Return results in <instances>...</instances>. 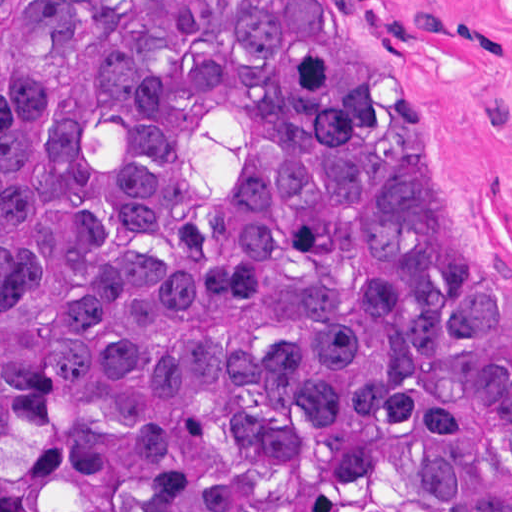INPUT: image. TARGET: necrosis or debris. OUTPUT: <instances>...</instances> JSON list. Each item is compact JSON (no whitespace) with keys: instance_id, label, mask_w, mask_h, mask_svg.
<instances>
[{"instance_id":"1","label":"necrosis or debris","mask_w":512,"mask_h":512,"mask_svg":"<svg viewBox=\"0 0 512 512\" xmlns=\"http://www.w3.org/2000/svg\"><path fill=\"white\" fill-rule=\"evenodd\" d=\"M0 512H26L16 500L0 462Z\"/></svg>"}]
</instances>
